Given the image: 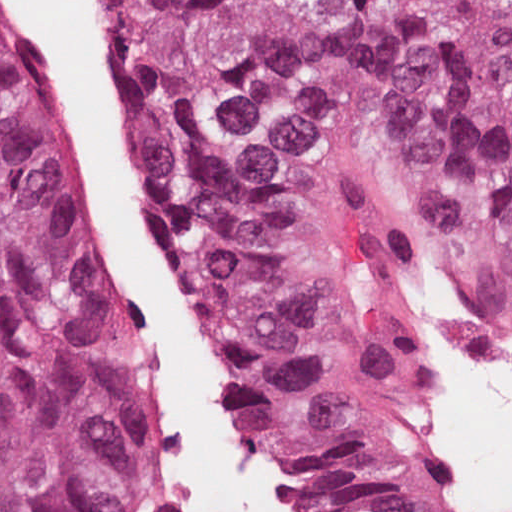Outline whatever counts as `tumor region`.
I'll list each match as a JSON object with an SVG mask.
<instances>
[{"label": "tumor region", "mask_w": 512, "mask_h": 512, "mask_svg": "<svg viewBox=\"0 0 512 512\" xmlns=\"http://www.w3.org/2000/svg\"><path fill=\"white\" fill-rule=\"evenodd\" d=\"M235 427L307 512H436L401 213L512 298V0H103ZM158 415L117 225L0 20V512H135Z\"/></svg>", "instance_id": "1"}]
</instances>
